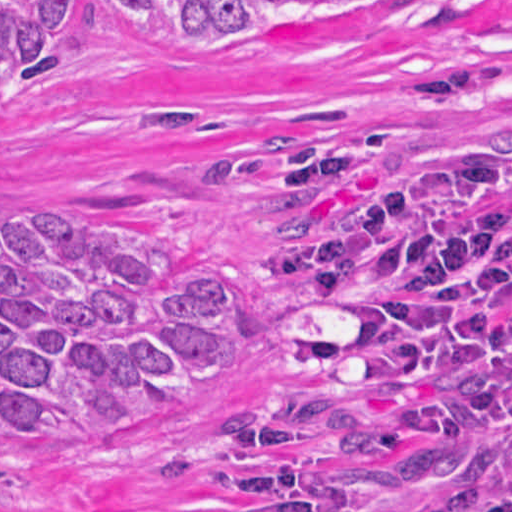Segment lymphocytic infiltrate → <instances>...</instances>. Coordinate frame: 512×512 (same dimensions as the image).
Listing matches in <instances>:
<instances>
[{
  "label": "lymphocytic infiltrate",
  "instance_id": "lymphocytic-infiltrate-1",
  "mask_svg": "<svg viewBox=\"0 0 512 512\" xmlns=\"http://www.w3.org/2000/svg\"><path fill=\"white\" fill-rule=\"evenodd\" d=\"M511 170H512V165H511ZM269 175H270V171H269ZM269 196L274 201V203L276 204V207L279 209V211L284 213V214H286V198H284V197L279 195V193L276 190V187H274V185L272 184L270 179H269ZM278 263H279V260H278V262L276 264V269L274 271V274L276 276V281H277V283L282 284L283 289H284L285 294H286V297L288 298V300L292 304L294 302L298 301V300H326V299H322V298H319V297L308 296V295H305V294H303L301 292H298V291L292 289L290 287V285L285 281V279L277 271ZM316 302L328 304V305H331V306H334V307H338V308H342V309H346V310H353L351 308V306L346 304V303L335 302V301H316ZM375 327H376L377 337H379L382 340L386 341V343H388L390 345L403 348L398 343H396L395 341H393L390 338H388L376 325H375Z\"/></svg>",
  "mask_w": 512,
  "mask_h": 512
}]
</instances>
